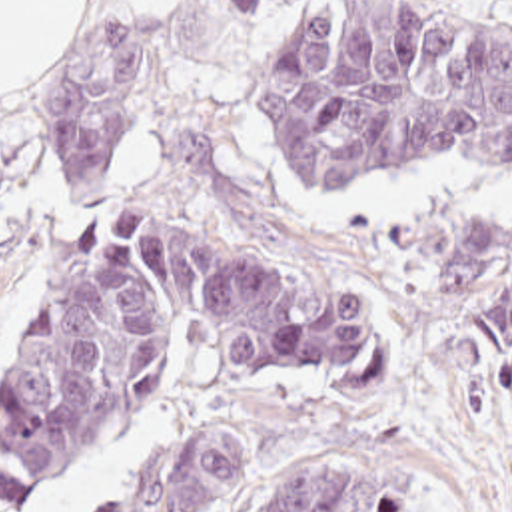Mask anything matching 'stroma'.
Wrapping results in <instances>:
<instances>
[{"label":"stroma","mask_w":512,"mask_h":512,"mask_svg":"<svg viewBox=\"0 0 512 512\" xmlns=\"http://www.w3.org/2000/svg\"><path fill=\"white\" fill-rule=\"evenodd\" d=\"M318 0H91L67 53L0 99V385L51 297L77 229L153 211L348 291L360 345L316 371L241 379L205 343L171 359L131 415L13 512H95L179 439L223 429L247 482L237 512L316 452L384 460L428 512H512V371H486L474 333L436 299L424 213L512 219V179L470 163L414 167L354 191H301L245 111L239 81ZM512 15V0H444ZM91 29L137 31L135 117L93 195L59 185L49 103Z\"/></svg>","instance_id":"1"}]
</instances>
